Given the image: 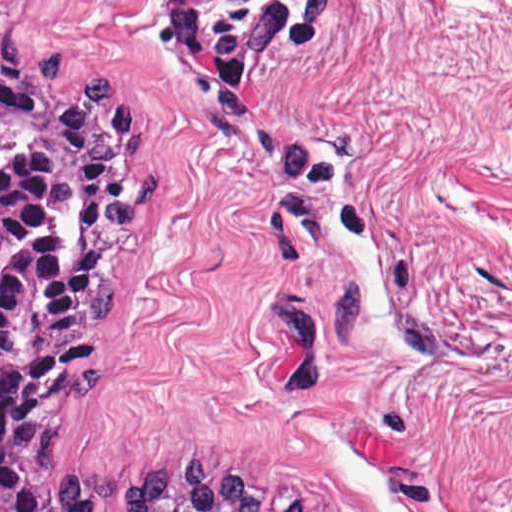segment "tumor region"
<instances>
[{
  "mask_svg": "<svg viewBox=\"0 0 512 512\" xmlns=\"http://www.w3.org/2000/svg\"><path fill=\"white\" fill-rule=\"evenodd\" d=\"M65 50L0 34V512H301L194 451L166 473L84 469L76 408L108 386V340L155 213L157 153L102 68L72 93Z\"/></svg>",
  "mask_w": 512,
  "mask_h": 512,
  "instance_id": "1",
  "label": "tumor region"
}]
</instances>
